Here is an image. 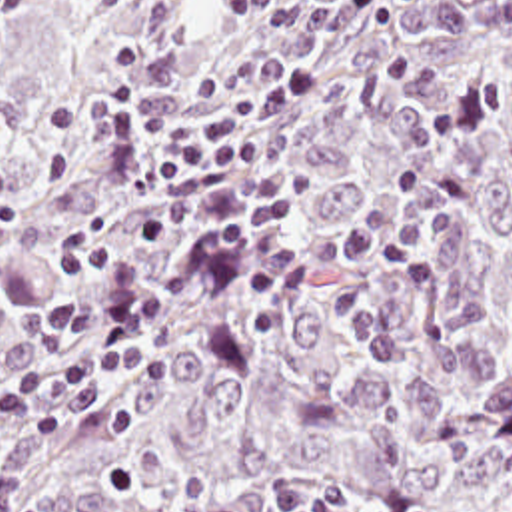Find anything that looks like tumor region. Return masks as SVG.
Returning a JSON list of instances; mask_svg holds the SVG:
<instances>
[{
    "label": "tumor region",
    "instance_id": "e687c5a6",
    "mask_svg": "<svg viewBox=\"0 0 512 512\" xmlns=\"http://www.w3.org/2000/svg\"><path fill=\"white\" fill-rule=\"evenodd\" d=\"M161 36L201 86L225 56L297 66L277 126L297 240L351 232L421 168L455 208L441 290L337 276L387 326L395 368L305 292L261 332L235 278L197 280L151 344L163 366L79 386L65 439L3 435L43 512H512V0H45L0 44V364L57 348L29 328L59 296L49 256L93 222L137 260L161 190L115 182L81 108L119 82L111 48Z\"/></svg>",
    "mask_w": 512,
    "mask_h": 512
}]
</instances>
